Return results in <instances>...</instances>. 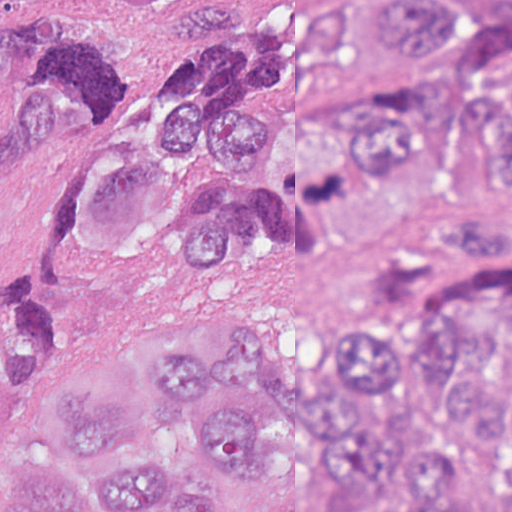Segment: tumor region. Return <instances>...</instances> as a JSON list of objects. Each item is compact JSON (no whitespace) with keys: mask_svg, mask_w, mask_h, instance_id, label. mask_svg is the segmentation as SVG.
I'll return each instance as SVG.
<instances>
[{"mask_svg":"<svg viewBox=\"0 0 512 512\" xmlns=\"http://www.w3.org/2000/svg\"><path fill=\"white\" fill-rule=\"evenodd\" d=\"M512 1H0V512H233L265 385L345 493L465 512L466 444L512 420ZM272 255L347 302L446 267L437 309L291 341L202 288L151 319L195 443L165 453L109 384L61 451L41 390L89 300Z\"/></svg>","mask_w":512,"mask_h":512,"instance_id":"tumor-region-1","label":"tumor region"}]
</instances>
